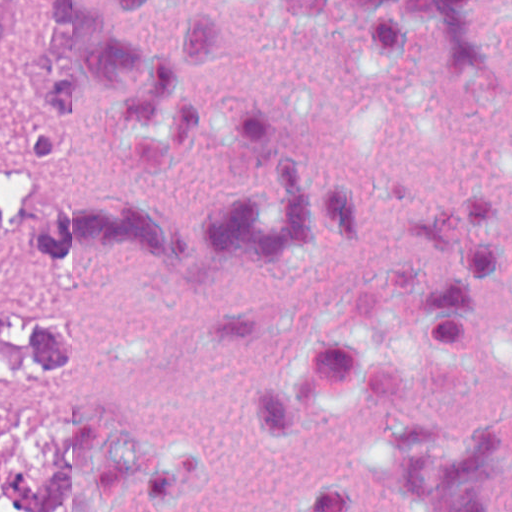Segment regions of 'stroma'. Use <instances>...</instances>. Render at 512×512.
<instances>
[{
    "label": "stroma",
    "mask_w": 512,
    "mask_h": 512,
    "mask_svg": "<svg viewBox=\"0 0 512 512\" xmlns=\"http://www.w3.org/2000/svg\"><path fill=\"white\" fill-rule=\"evenodd\" d=\"M13 2L25 31V55L10 97L16 133L0 136V181L53 187L49 131L36 115L26 81L38 38L41 0ZM0 293L33 310L52 313V260L32 248H0Z\"/></svg>",
    "instance_id": "35a3bbf8"
}]
</instances>
